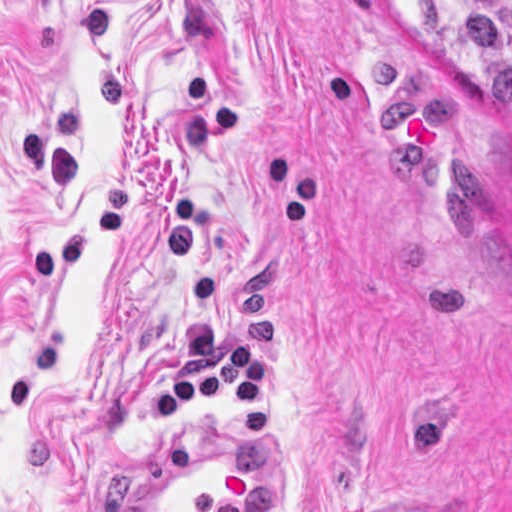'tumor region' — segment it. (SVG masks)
<instances>
[{
  "label": "tumor region",
  "mask_w": 512,
  "mask_h": 512,
  "mask_svg": "<svg viewBox=\"0 0 512 512\" xmlns=\"http://www.w3.org/2000/svg\"><path fill=\"white\" fill-rule=\"evenodd\" d=\"M444 2L494 109L512 111V0Z\"/></svg>",
  "instance_id": "e687c5a6"
}]
</instances>
